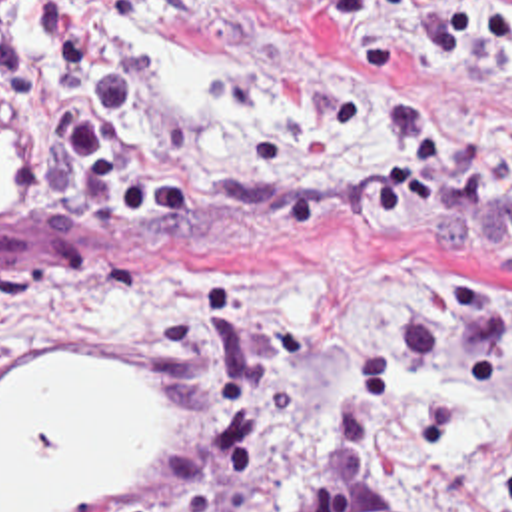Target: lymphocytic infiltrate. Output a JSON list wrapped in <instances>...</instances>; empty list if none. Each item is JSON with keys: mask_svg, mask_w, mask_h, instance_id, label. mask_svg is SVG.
Instances as JSON below:
<instances>
[{"mask_svg": "<svg viewBox=\"0 0 512 512\" xmlns=\"http://www.w3.org/2000/svg\"><path fill=\"white\" fill-rule=\"evenodd\" d=\"M153 2L0 0V154L35 196L31 240L0 258V321L119 281L85 212L187 256L377 240L387 283L331 369L291 512H393L381 487L393 395L460 411L512 381V276L415 266L512 258V140L470 148L427 88L512 80V0H311L369 46L375 116L349 156L279 202L235 192L207 144L153 110L137 38Z\"/></svg>", "mask_w": 512, "mask_h": 512, "instance_id": "1", "label": "lymphocytic infiltrate"}]
</instances>
